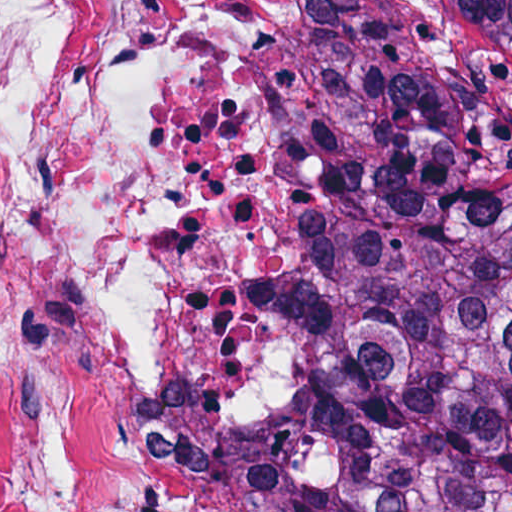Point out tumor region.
I'll use <instances>...</instances> for the list:
<instances>
[{"label": "tumor region", "mask_w": 512, "mask_h": 512, "mask_svg": "<svg viewBox=\"0 0 512 512\" xmlns=\"http://www.w3.org/2000/svg\"><path fill=\"white\" fill-rule=\"evenodd\" d=\"M188 512H512V0H370L327 332L275 435Z\"/></svg>", "instance_id": "1"}]
</instances>
